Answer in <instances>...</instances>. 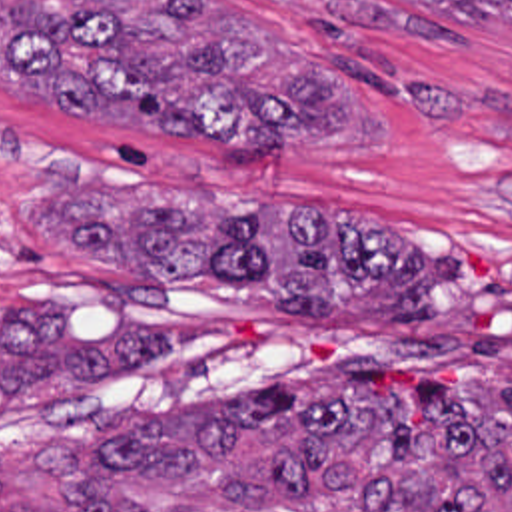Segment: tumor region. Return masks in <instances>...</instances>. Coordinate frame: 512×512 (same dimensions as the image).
<instances>
[{"instance_id": "obj_1", "label": "tumor region", "mask_w": 512, "mask_h": 512, "mask_svg": "<svg viewBox=\"0 0 512 512\" xmlns=\"http://www.w3.org/2000/svg\"><path fill=\"white\" fill-rule=\"evenodd\" d=\"M462 22L512 28V0H408ZM0 84L65 116L148 110L160 140L208 138L222 168H272L282 142H382V110L286 36L212 0H0ZM29 228L63 252L150 284L216 278L286 322L390 324L442 316V258H422L374 220L296 214L244 196L137 190L55 196ZM13 304L0 340V421L25 382H93L178 344V326L123 318L71 340L49 302ZM358 360L330 372L148 413L101 437L97 483L69 449L35 441L49 481L0 479L29 512H512V338L462 346L450 380L408 399L374 391ZM57 483L115 491L65 495ZM0 512H9L1 507Z\"/></svg>"}]
</instances>
